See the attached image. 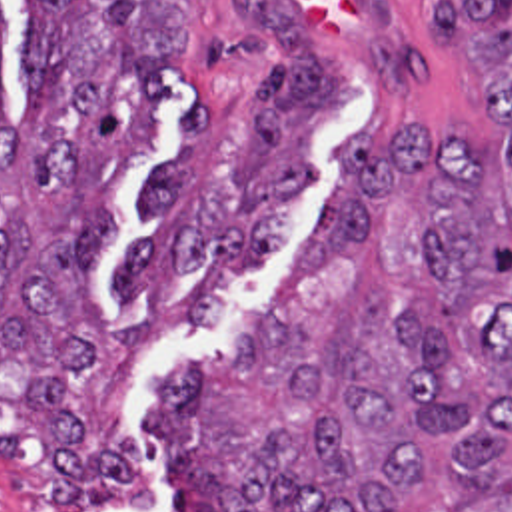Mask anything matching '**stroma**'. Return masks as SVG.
Returning a JSON list of instances; mask_svg holds the SVG:
<instances>
[{
  "label": "stroma",
  "mask_w": 512,
  "mask_h": 512,
  "mask_svg": "<svg viewBox=\"0 0 512 512\" xmlns=\"http://www.w3.org/2000/svg\"><path fill=\"white\" fill-rule=\"evenodd\" d=\"M178 2L182 66L164 76L168 108L154 120L152 154L118 176L108 194L112 236L96 268L108 324L90 386L94 424L100 430L122 424L138 439L154 479V499L144 511L88 512H226L172 471L170 455L156 443L154 416L172 372L196 360H220L260 336L284 278L334 204L340 146L350 134L370 138L376 152L412 124L442 140L498 142L474 106L468 50L436 40L426 0H274L318 42L348 92V108L314 134V182L290 206L286 236L266 274L220 284L210 330H196L190 306L212 272V258L202 264V280L162 282L124 302L116 280L134 248L154 232L140 216L144 180L180 156L184 124L204 100L210 122L196 142L200 188L222 206L240 208L234 162L248 150L252 104L282 54L276 42L240 22L242 0ZM30 28L32 0H4L6 112L16 122L24 110L18 78ZM46 469L36 436L0 408V512H60L40 487Z\"/></svg>",
  "instance_id": "35a3bbf8"
}]
</instances>
